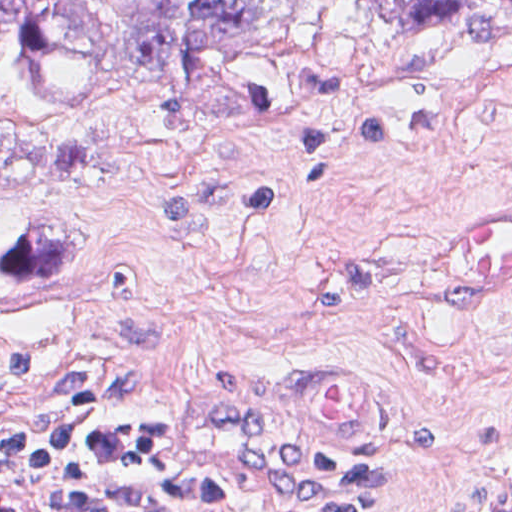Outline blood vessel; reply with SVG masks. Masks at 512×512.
I'll use <instances>...</instances> for the list:
<instances>
[{
    "instance_id": "1",
    "label": "blood vessel",
    "mask_w": 512,
    "mask_h": 512,
    "mask_svg": "<svg viewBox=\"0 0 512 512\" xmlns=\"http://www.w3.org/2000/svg\"><path fill=\"white\" fill-rule=\"evenodd\" d=\"M431 270L439 284L458 293H512V205L438 231Z\"/></svg>"
}]
</instances>
